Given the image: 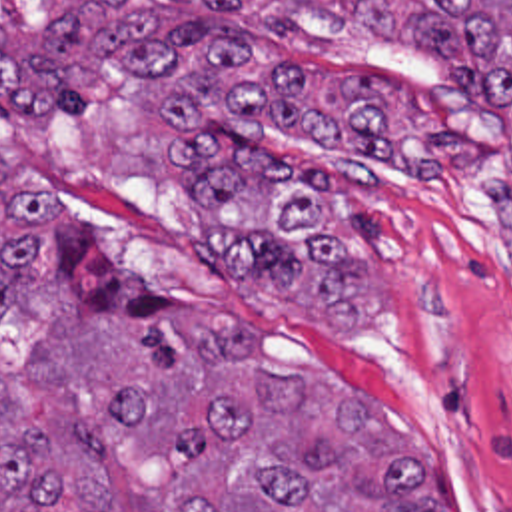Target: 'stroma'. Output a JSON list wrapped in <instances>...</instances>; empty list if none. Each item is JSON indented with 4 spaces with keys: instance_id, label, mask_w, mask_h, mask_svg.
<instances>
[{
    "instance_id": "obj_1",
    "label": "stroma",
    "mask_w": 512,
    "mask_h": 512,
    "mask_svg": "<svg viewBox=\"0 0 512 512\" xmlns=\"http://www.w3.org/2000/svg\"><path fill=\"white\" fill-rule=\"evenodd\" d=\"M240 1L244 29L266 55H286L336 85H364L395 41L340 27L292 1ZM148 109L136 79L110 73L76 111L6 105L0 131L64 187L100 245L168 293L226 305L246 321L176 311L188 345L258 339L286 361L350 381L403 428L455 512H512V227L485 139H463L429 161L391 153L352 161L354 217L371 255V313L360 327L314 329L216 271L150 209L142 143ZM318 147V139L266 129L250 153L298 177ZM0 189L26 227L54 303L96 333L130 343L118 325L76 311L60 291L52 199L2 157ZM220 257L232 267V245ZM373 432L429 502L407 444Z\"/></svg>"
}]
</instances>
